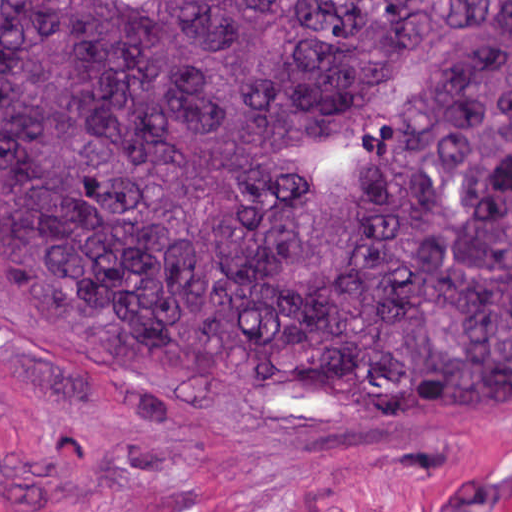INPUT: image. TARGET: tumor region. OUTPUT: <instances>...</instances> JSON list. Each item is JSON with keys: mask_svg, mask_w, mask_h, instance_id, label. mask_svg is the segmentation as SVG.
Returning <instances> with one entry per match:
<instances>
[{"mask_svg": "<svg viewBox=\"0 0 512 512\" xmlns=\"http://www.w3.org/2000/svg\"><path fill=\"white\" fill-rule=\"evenodd\" d=\"M0 289L94 346L512 417V0H0Z\"/></svg>", "mask_w": 512, "mask_h": 512, "instance_id": "1", "label": "tumor region"}]
</instances>
